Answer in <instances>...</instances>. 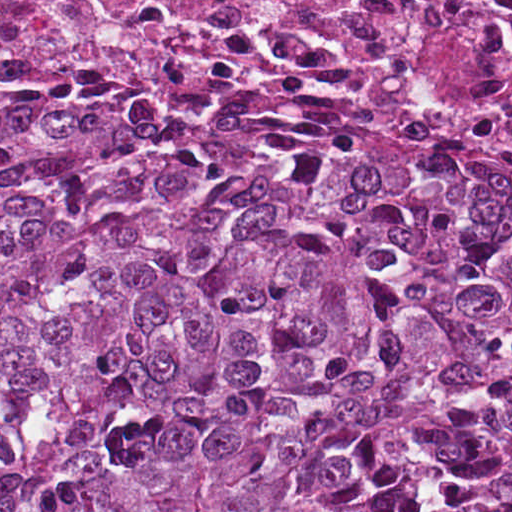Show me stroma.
Segmentation results:
<instances>
[{"label":"stroma","mask_w":512,"mask_h":512,"mask_svg":"<svg viewBox=\"0 0 512 512\" xmlns=\"http://www.w3.org/2000/svg\"><path fill=\"white\" fill-rule=\"evenodd\" d=\"M70 78H230L243 83H292L331 92L357 106L390 111L437 124L461 133L490 161L512 168V145L485 136L448 117L408 101L315 79L246 68H221L198 73H140L121 68H14L0 71V84L16 81H56Z\"/></svg>","instance_id":"obj_1"}]
</instances>
